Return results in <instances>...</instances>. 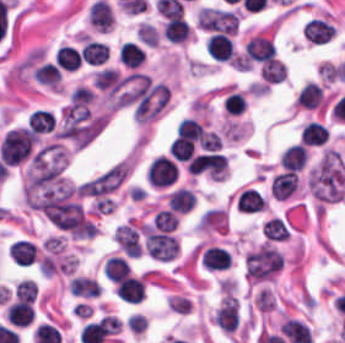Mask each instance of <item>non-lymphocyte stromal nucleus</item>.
I'll list each match as a JSON object with an SVG mask.
<instances>
[{
  "label": "non-lymphocyte stromal nucleus",
  "instance_id": "obj_1",
  "mask_svg": "<svg viewBox=\"0 0 345 343\" xmlns=\"http://www.w3.org/2000/svg\"><path fill=\"white\" fill-rule=\"evenodd\" d=\"M311 195L318 204L340 199L345 189V173L339 153L326 150L309 177Z\"/></svg>",
  "mask_w": 345,
  "mask_h": 343
}]
</instances>
